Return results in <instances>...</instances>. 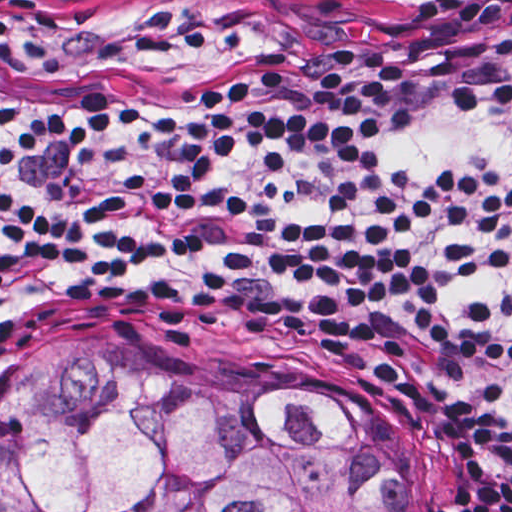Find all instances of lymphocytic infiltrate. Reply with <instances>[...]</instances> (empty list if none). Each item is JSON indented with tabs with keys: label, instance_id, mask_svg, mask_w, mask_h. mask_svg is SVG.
I'll return each instance as SVG.
<instances>
[{
	"label": "lymphocytic infiltrate",
	"instance_id": "lymphocytic-infiltrate-1",
	"mask_svg": "<svg viewBox=\"0 0 512 512\" xmlns=\"http://www.w3.org/2000/svg\"><path fill=\"white\" fill-rule=\"evenodd\" d=\"M56 311L364 342L512 495V0H1V324Z\"/></svg>",
	"mask_w": 512,
	"mask_h": 512
}]
</instances>
